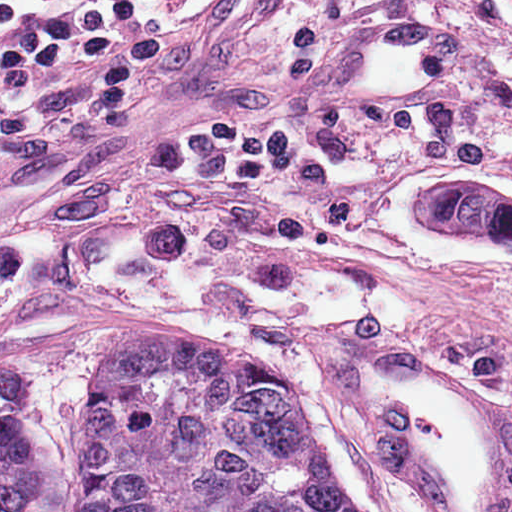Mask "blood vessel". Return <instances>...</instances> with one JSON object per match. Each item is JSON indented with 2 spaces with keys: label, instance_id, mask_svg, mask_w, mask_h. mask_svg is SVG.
Wrapping results in <instances>:
<instances>
[{
  "label": "blood vessel",
  "instance_id": "obj_1",
  "mask_svg": "<svg viewBox=\"0 0 512 512\" xmlns=\"http://www.w3.org/2000/svg\"><path fill=\"white\" fill-rule=\"evenodd\" d=\"M302 89L311 104L413 103L379 19L323 38ZM305 363L417 512H512L509 383L452 348L326 331Z\"/></svg>",
  "mask_w": 512,
  "mask_h": 512
}]
</instances>
